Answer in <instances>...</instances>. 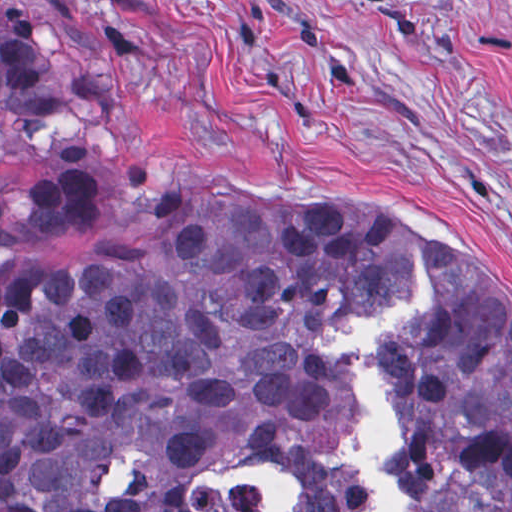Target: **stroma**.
Here are the masks:
<instances>
[{
    "label": "stroma",
    "mask_w": 512,
    "mask_h": 512,
    "mask_svg": "<svg viewBox=\"0 0 512 512\" xmlns=\"http://www.w3.org/2000/svg\"><path fill=\"white\" fill-rule=\"evenodd\" d=\"M92 128L0 149V184L94 173L63 264L163 189L228 184L466 241L512 303V0H0Z\"/></svg>",
    "instance_id": "35a3bbf8"
}]
</instances>
